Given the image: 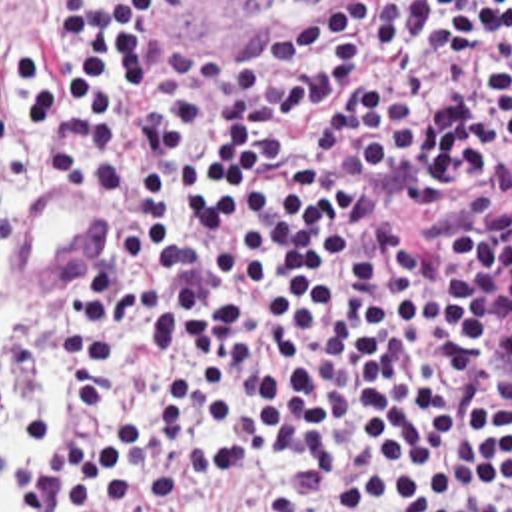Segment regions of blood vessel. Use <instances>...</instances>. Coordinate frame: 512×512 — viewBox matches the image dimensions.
I'll return each instance as SVG.
<instances>
[{
	"instance_id": "obj_1",
	"label": "blood vessel",
	"mask_w": 512,
	"mask_h": 512,
	"mask_svg": "<svg viewBox=\"0 0 512 512\" xmlns=\"http://www.w3.org/2000/svg\"><path fill=\"white\" fill-rule=\"evenodd\" d=\"M205 30H264L300 20L334 0H153ZM111 196L67 176L33 184L21 200L9 242L15 292L37 298L83 274L103 248Z\"/></svg>"
}]
</instances>
